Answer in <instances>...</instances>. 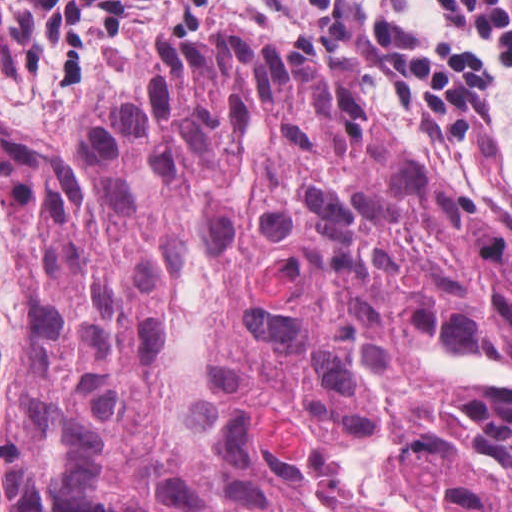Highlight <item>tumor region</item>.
Instances as JSON below:
<instances>
[{
  "label": "tumor region",
  "instance_id": "e687c5a6",
  "mask_svg": "<svg viewBox=\"0 0 512 512\" xmlns=\"http://www.w3.org/2000/svg\"><path fill=\"white\" fill-rule=\"evenodd\" d=\"M0 200L9 512H512V227L316 71L163 48Z\"/></svg>",
  "mask_w": 512,
  "mask_h": 512
}]
</instances>
